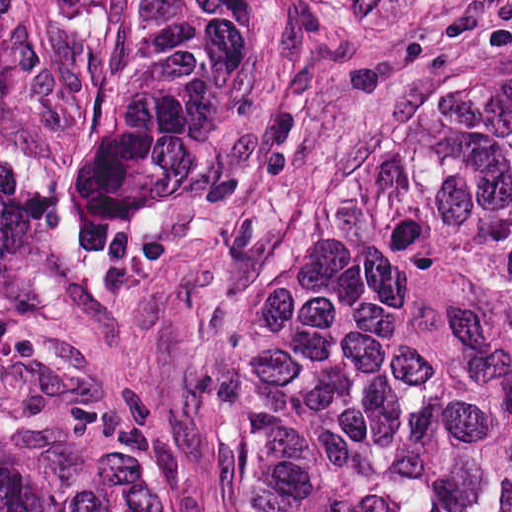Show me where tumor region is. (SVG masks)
Here are the masks:
<instances>
[{
    "label": "tumor region",
    "instance_id": "obj_1",
    "mask_svg": "<svg viewBox=\"0 0 512 512\" xmlns=\"http://www.w3.org/2000/svg\"><path fill=\"white\" fill-rule=\"evenodd\" d=\"M0 512H170L73 401H0ZM221 512H512V410L221 316Z\"/></svg>",
    "mask_w": 512,
    "mask_h": 512
}]
</instances>
